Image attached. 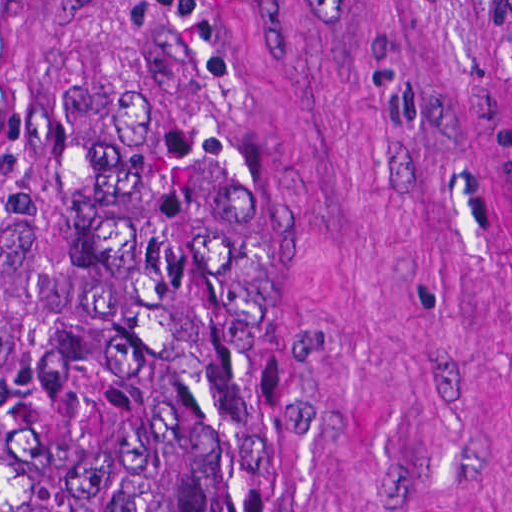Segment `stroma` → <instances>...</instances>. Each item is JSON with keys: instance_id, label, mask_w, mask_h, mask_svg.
Wrapping results in <instances>:
<instances>
[{"instance_id": "35a3bbf8", "label": "stroma", "mask_w": 512, "mask_h": 512, "mask_svg": "<svg viewBox=\"0 0 512 512\" xmlns=\"http://www.w3.org/2000/svg\"><path fill=\"white\" fill-rule=\"evenodd\" d=\"M248 166L214 512H512V150L480 0H181ZM138 0H0V386Z\"/></svg>"}]
</instances>
